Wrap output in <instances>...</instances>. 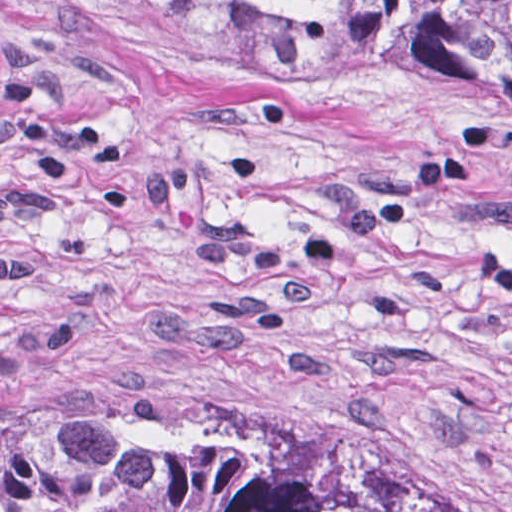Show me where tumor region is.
<instances>
[{
    "instance_id": "1",
    "label": "tumor region",
    "mask_w": 512,
    "mask_h": 512,
    "mask_svg": "<svg viewBox=\"0 0 512 512\" xmlns=\"http://www.w3.org/2000/svg\"><path fill=\"white\" fill-rule=\"evenodd\" d=\"M77 13L197 77L512 110V0H0ZM0 512H499L353 444L141 372L0 384Z\"/></svg>"
}]
</instances>
